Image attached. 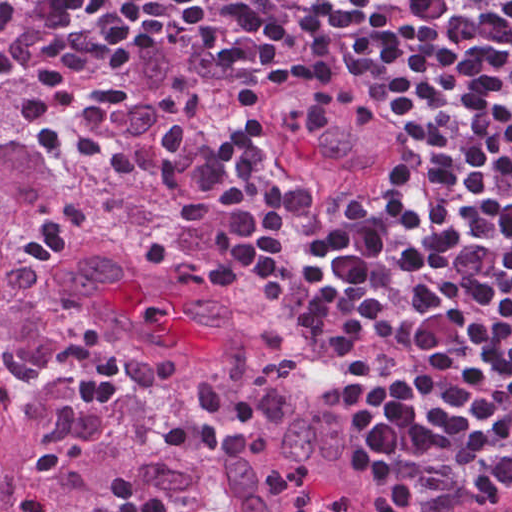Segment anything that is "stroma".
Listing matches in <instances>:
<instances>
[{"mask_svg": "<svg viewBox=\"0 0 512 512\" xmlns=\"http://www.w3.org/2000/svg\"><path fill=\"white\" fill-rule=\"evenodd\" d=\"M39 158L40 190L75 183L89 176L58 133L25 109L5 133ZM300 369L313 387L336 403L357 379L362 361L318 340L286 329ZM399 512H504L512 507V489L464 494L405 483H384Z\"/></svg>", "mask_w": 512, "mask_h": 512, "instance_id": "1", "label": "stroma"}]
</instances>
